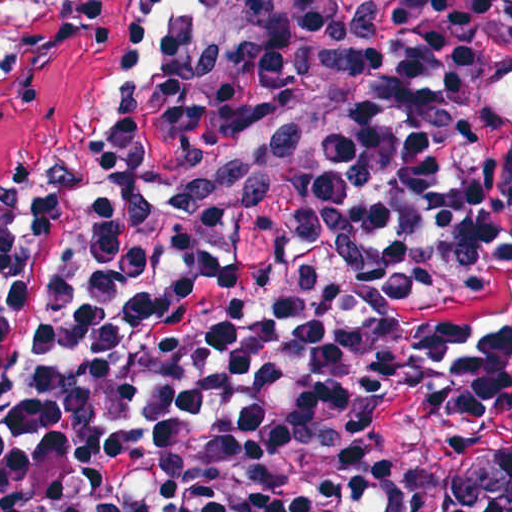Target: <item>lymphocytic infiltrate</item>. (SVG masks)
Instances as JSON below:
<instances>
[{"label": "lymphocytic infiltrate", "mask_w": 512, "mask_h": 512, "mask_svg": "<svg viewBox=\"0 0 512 512\" xmlns=\"http://www.w3.org/2000/svg\"><path fill=\"white\" fill-rule=\"evenodd\" d=\"M144 7L0 183V512H427L366 433L512 378V0Z\"/></svg>", "instance_id": "obj_1"}]
</instances>
